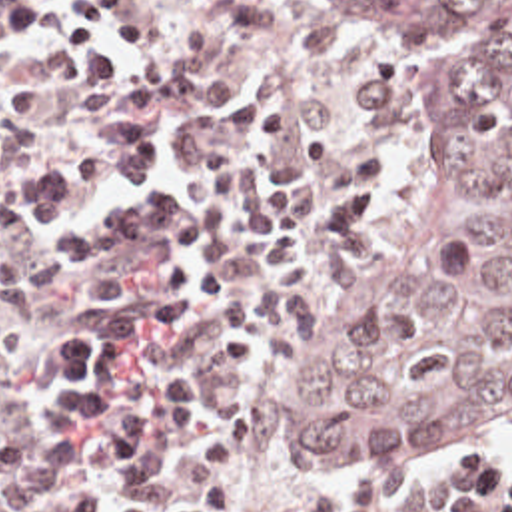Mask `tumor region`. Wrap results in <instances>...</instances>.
I'll list each match as a JSON object with an SVG mask.
<instances>
[{
  "instance_id": "1",
  "label": "tumor region",
  "mask_w": 512,
  "mask_h": 512,
  "mask_svg": "<svg viewBox=\"0 0 512 512\" xmlns=\"http://www.w3.org/2000/svg\"><path fill=\"white\" fill-rule=\"evenodd\" d=\"M374 35L416 93V185L327 301L267 446L408 468L512 430V0H299Z\"/></svg>"
}]
</instances>
